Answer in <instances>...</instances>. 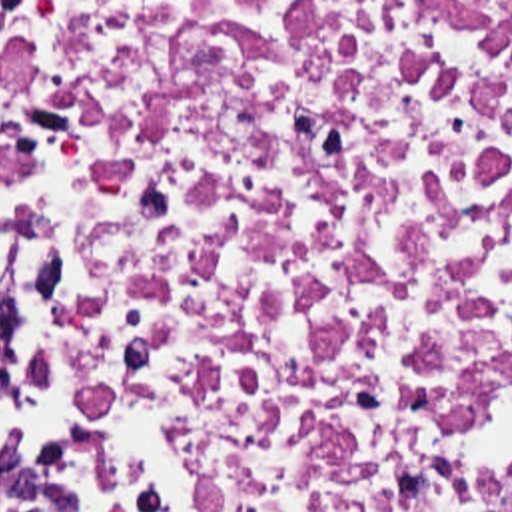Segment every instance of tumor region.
Wrapping results in <instances>:
<instances>
[{"label": "tumor region", "mask_w": 512, "mask_h": 512, "mask_svg": "<svg viewBox=\"0 0 512 512\" xmlns=\"http://www.w3.org/2000/svg\"><path fill=\"white\" fill-rule=\"evenodd\" d=\"M9 351V305L0 293V371ZM0 512H51L29 475L0 447Z\"/></svg>", "instance_id": "tumor-region-1"}]
</instances>
